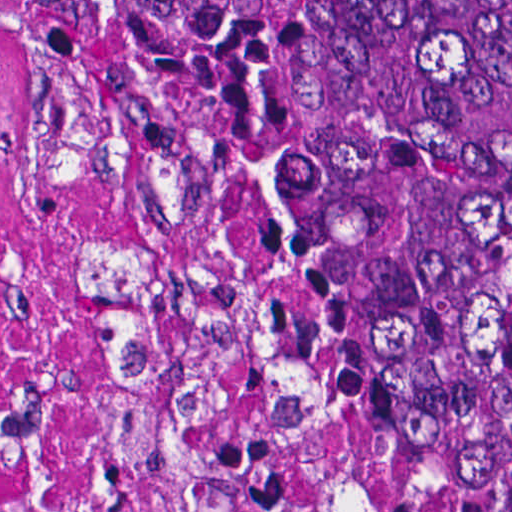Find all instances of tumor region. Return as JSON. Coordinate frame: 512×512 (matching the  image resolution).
<instances>
[{
	"mask_svg": "<svg viewBox=\"0 0 512 512\" xmlns=\"http://www.w3.org/2000/svg\"><path fill=\"white\" fill-rule=\"evenodd\" d=\"M384 394L504 368L469 512H512V0H20Z\"/></svg>",
	"mask_w": 512,
	"mask_h": 512,
	"instance_id": "e687c5a6",
	"label": "tumor region"
}]
</instances>
